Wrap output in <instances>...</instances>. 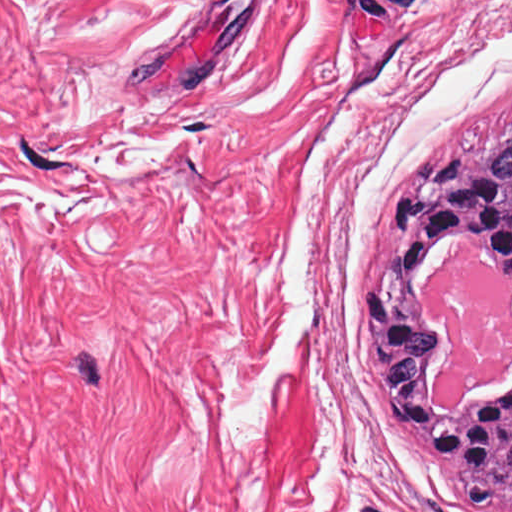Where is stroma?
<instances>
[{
    "instance_id": "1",
    "label": "stroma",
    "mask_w": 512,
    "mask_h": 512,
    "mask_svg": "<svg viewBox=\"0 0 512 512\" xmlns=\"http://www.w3.org/2000/svg\"><path fill=\"white\" fill-rule=\"evenodd\" d=\"M511 128L512 0H0V512H474L353 304Z\"/></svg>"
}]
</instances>
